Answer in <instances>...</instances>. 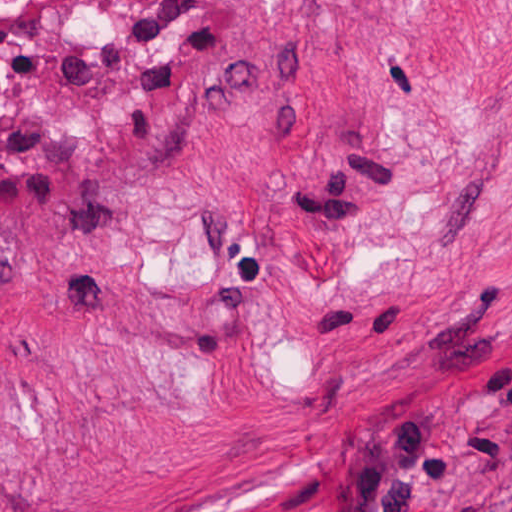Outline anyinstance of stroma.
<instances>
[{
	"label": "stroma",
	"mask_w": 512,
	"mask_h": 512,
	"mask_svg": "<svg viewBox=\"0 0 512 512\" xmlns=\"http://www.w3.org/2000/svg\"><path fill=\"white\" fill-rule=\"evenodd\" d=\"M512 0H0V512H498Z\"/></svg>",
	"instance_id": "stroma-1"
}]
</instances>
